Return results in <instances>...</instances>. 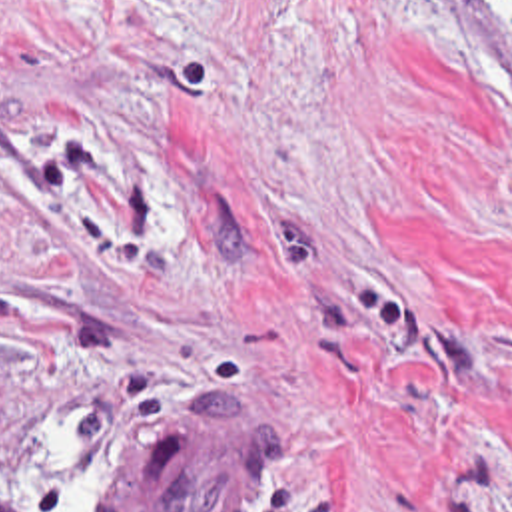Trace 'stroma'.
I'll return each instance as SVG.
<instances>
[{
    "mask_svg": "<svg viewBox=\"0 0 512 512\" xmlns=\"http://www.w3.org/2000/svg\"><path fill=\"white\" fill-rule=\"evenodd\" d=\"M199 398L252 512H512V0H0V512Z\"/></svg>",
    "mask_w": 512,
    "mask_h": 512,
    "instance_id": "35a3bbf8",
    "label": "stroma"
}]
</instances>
